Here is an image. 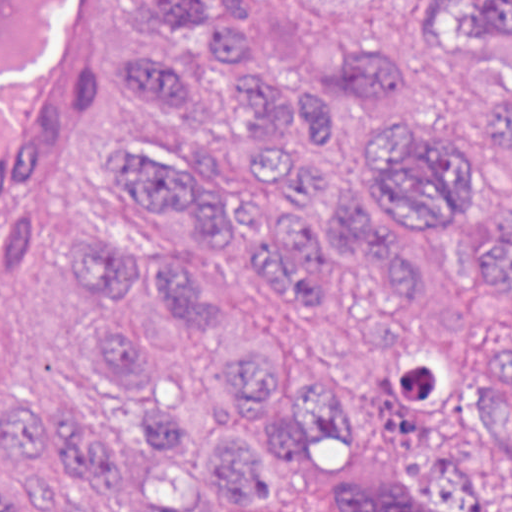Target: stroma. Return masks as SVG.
Here are the masks:
<instances>
[{
    "label": "stroma",
    "mask_w": 512,
    "mask_h": 512,
    "mask_svg": "<svg viewBox=\"0 0 512 512\" xmlns=\"http://www.w3.org/2000/svg\"><path fill=\"white\" fill-rule=\"evenodd\" d=\"M257 4L274 66L308 88L329 84L350 53L410 65L414 86L405 106L342 114L320 150L317 169L327 187L366 182L386 124L471 129L484 88L512 89V66L430 39L421 0ZM153 41L147 0H86L47 99L0 169V402L19 388L73 405L98 423L143 427L165 392H206L224 356L282 341L337 377L346 420L335 441L278 465L279 487L298 512H334L354 470L378 469L388 456L374 365L391 355L403 307L354 281L325 313L288 311L234 238L222 254L202 250L198 229L177 214L155 225V249L195 253L214 265L238 296V321L227 340L186 333L162 297L144 293L151 353L144 376L124 391L83 363V345L107 323L100 306L80 301L70 285L67 244L83 229L142 222L99 172L103 155L139 137L115 82L119 61ZM485 196L494 214L512 221V175H489ZM377 220L422 277L426 289L408 310L423 325L459 340L501 338V320H512V289L500 293L479 280L457 226ZM15 466L0 438V469Z\"/></svg>",
    "instance_id": "1"
}]
</instances>
